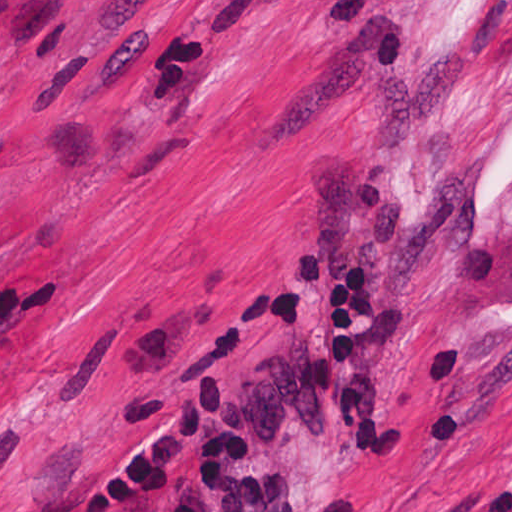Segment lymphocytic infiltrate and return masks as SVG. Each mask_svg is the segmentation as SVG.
<instances>
[{"instance_id":"lymphocytic-infiltrate-1","label":"lymphocytic infiltrate","mask_w":512,"mask_h":512,"mask_svg":"<svg viewBox=\"0 0 512 512\" xmlns=\"http://www.w3.org/2000/svg\"><path fill=\"white\" fill-rule=\"evenodd\" d=\"M362 263L367 262H338L330 268L324 332L308 356V388L364 466H389L401 447L402 431L388 430L357 366V339L377 315L376 282Z\"/></svg>"}]
</instances>
